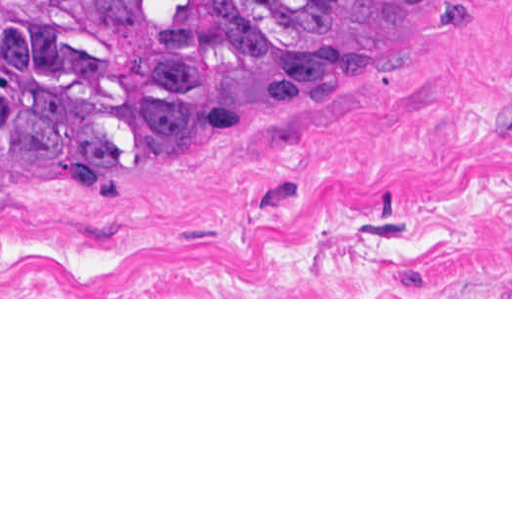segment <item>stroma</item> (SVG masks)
Here are the masks:
<instances>
[{"label":"stroma","instance_id":"stroma-1","mask_svg":"<svg viewBox=\"0 0 512 512\" xmlns=\"http://www.w3.org/2000/svg\"><path fill=\"white\" fill-rule=\"evenodd\" d=\"M0 299H512V0L178 160L0 161Z\"/></svg>","mask_w":512,"mask_h":512}]
</instances>
